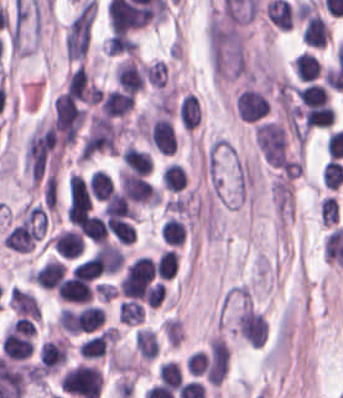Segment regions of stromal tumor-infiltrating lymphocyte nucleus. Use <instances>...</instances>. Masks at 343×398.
Returning <instances> with one entry per match:
<instances>
[{
    "label": "stromal tumor-infiltrating lymphocyte nucleus",
    "instance_id": "1",
    "mask_svg": "<svg viewBox=\"0 0 343 398\" xmlns=\"http://www.w3.org/2000/svg\"><path fill=\"white\" fill-rule=\"evenodd\" d=\"M56 291L64 303H90L95 291L93 276L82 264H75L56 286Z\"/></svg>",
    "mask_w": 343,
    "mask_h": 398
},
{
    "label": "stromal tumor-infiltrating lymphocyte nucleus",
    "instance_id": "2",
    "mask_svg": "<svg viewBox=\"0 0 343 398\" xmlns=\"http://www.w3.org/2000/svg\"><path fill=\"white\" fill-rule=\"evenodd\" d=\"M235 107L242 122H257L271 109L266 92L252 86H245L235 93Z\"/></svg>",
    "mask_w": 343,
    "mask_h": 398
},
{
    "label": "stromal tumor-infiltrating lymphocyte nucleus",
    "instance_id": "3",
    "mask_svg": "<svg viewBox=\"0 0 343 398\" xmlns=\"http://www.w3.org/2000/svg\"><path fill=\"white\" fill-rule=\"evenodd\" d=\"M148 141L161 154H173L176 146L173 122L168 114L155 113L146 125Z\"/></svg>",
    "mask_w": 343,
    "mask_h": 398
},
{
    "label": "stromal tumor-infiltrating lymphocyte nucleus",
    "instance_id": "4",
    "mask_svg": "<svg viewBox=\"0 0 343 398\" xmlns=\"http://www.w3.org/2000/svg\"><path fill=\"white\" fill-rule=\"evenodd\" d=\"M155 263L145 256L136 257L125 269L120 290H144L154 279Z\"/></svg>",
    "mask_w": 343,
    "mask_h": 398
},
{
    "label": "stromal tumor-infiltrating lymphocyte nucleus",
    "instance_id": "5",
    "mask_svg": "<svg viewBox=\"0 0 343 398\" xmlns=\"http://www.w3.org/2000/svg\"><path fill=\"white\" fill-rule=\"evenodd\" d=\"M65 274V264L59 258L49 257L33 271V283L43 289H56Z\"/></svg>",
    "mask_w": 343,
    "mask_h": 398
},
{
    "label": "stromal tumor-infiltrating lymphocyte nucleus",
    "instance_id": "6",
    "mask_svg": "<svg viewBox=\"0 0 343 398\" xmlns=\"http://www.w3.org/2000/svg\"><path fill=\"white\" fill-rule=\"evenodd\" d=\"M49 243L64 257L75 258L83 250V237L75 228H61L53 233Z\"/></svg>",
    "mask_w": 343,
    "mask_h": 398
},
{
    "label": "stromal tumor-infiltrating lymphocyte nucleus",
    "instance_id": "7",
    "mask_svg": "<svg viewBox=\"0 0 343 398\" xmlns=\"http://www.w3.org/2000/svg\"><path fill=\"white\" fill-rule=\"evenodd\" d=\"M122 157L127 169L146 175L153 169L152 154L148 149L127 143L122 149Z\"/></svg>",
    "mask_w": 343,
    "mask_h": 398
},
{
    "label": "stromal tumor-infiltrating lymphocyte nucleus",
    "instance_id": "8",
    "mask_svg": "<svg viewBox=\"0 0 343 398\" xmlns=\"http://www.w3.org/2000/svg\"><path fill=\"white\" fill-rule=\"evenodd\" d=\"M178 115L185 130L194 131L202 121L200 98L193 93H185L179 106Z\"/></svg>",
    "mask_w": 343,
    "mask_h": 398
},
{
    "label": "stromal tumor-infiltrating lymphocyte nucleus",
    "instance_id": "9",
    "mask_svg": "<svg viewBox=\"0 0 343 398\" xmlns=\"http://www.w3.org/2000/svg\"><path fill=\"white\" fill-rule=\"evenodd\" d=\"M299 110L308 128H325L333 125L335 113L328 103L299 106Z\"/></svg>",
    "mask_w": 343,
    "mask_h": 398
},
{
    "label": "stromal tumor-infiltrating lymphocyte nucleus",
    "instance_id": "10",
    "mask_svg": "<svg viewBox=\"0 0 343 398\" xmlns=\"http://www.w3.org/2000/svg\"><path fill=\"white\" fill-rule=\"evenodd\" d=\"M294 74L299 81H313L320 76L323 69L318 57L312 51H303L295 58Z\"/></svg>",
    "mask_w": 343,
    "mask_h": 398
},
{
    "label": "stromal tumor-infiltrating lymphocyte nucleus",
    "instance_id": "11",
    "mask_svg": "<svg viewBox=\"0 0 343 398\" xmlns=\"http://www.w3.org/2000/svg\"><path fill=\"white\" fill-rule=\"evenodd\" d=\"M1 349L13 360H25L34 351V343L28 335L3 336Z\"/></svg>",
    "mask_w": 343,
    "mask_h": 398
},
{
    "label": "stromal tumor-infiltrating lymphocyte nucleus",
    "instance_id": "12",
    "mask_svg": "<svg viewBox=\"0 0 343 398\" xmlns=\"http://www.w3.org/2000/svg\"><path fill=\"white\" fill-rule=\"evenodd\" d=\"M77 327L79 331H93L100 329L104 320V311L93 303H86L76 309Z\"/></svg>",
    "mask_w": 343,
    "mask_h": 398
},
{
    "label": "stromal tumor-infiltrating lymphocyte nucleus",
    "instance_id": "13",
    "mask_svg": "<svg viewBox=\"0 0 343 398\" xmlns=\"http://www.w3.org/2000/svg\"><path fill=\"white\" fill-rule=\"evenodd\" d=\"M136 351L139 358L151 360L158 355V336L147 326H139L136 331Z\"/></svg>",
    "mask_w": 343,
    "mask_h": 398
},
{
    "label": "stromal tumor-infiltrating lymphocyte nucleus",
    "instance_id": "14",
    "mask_svg": "<svg viewBox=\"0 0 343 398\" xmlns=\"http://www.w3.org/2000/svg\"><path fill=\"white\" fill-rule=\"evenodd\" d=\"M294 92L301 104L322 105L329 102V96L324 85L309 82L294 88Z\"/></svg>",
    "mask_w": 343,
    "mask_h": 398
},
{
    "label": "stromal tumor-infiltrating lymphocyte nucleus",
    "instance_id": "15",
    "mask_svg": "<svg viewBox=\"0 0 343 398\" xmlns=\"http://www.w3.org/2000/svg\"><path fill=\"white\" fill-rule=\"evenodd\" d=\"M161 237L168 246H181L186 237V227L179 217L167 216L162 227Z\"/></svg>",
    "mask_w": 343,
    "mask_h": 398
},
{
    "label": "stromal tumor-infiltrating lymphocyte nucleus",
    "instance_id": "16",
    "mask_svg": "<svg viewBox=\"0 0 343 398\" xmlns=\"http://www.w3.org/2000/svg\"><path fill=\"white\" fill-rule=\"evenodd\" d=\"M70 273L94 279L103 274L102 250H95L77 262Z\"/></svg>",
    "mask_w": 343,
    "mask_h": 398
},
{
    "label": "stromal tumor-infiltrating lymphocyte nucleus",
    "instance_id": "17",
    "mask_svg": "<svg viewBox=\"0 0 343 398\" xmlns=\"http://www.w3.org/2000/svg\"><path fill=\"white\" fill-rule=\"evenodd\" d=\"M100 251L104 272L114 274L121 269L124 263V254L121 246L113 242H100Z\"/></svg>",
    "mask_w": 343,
    "mask_h": 398
},
{
    "label": "stromal tumor-infiltrating lymphocyte nucleus",
    "instance_id": "18",
    "mask_svg": "<svg viewBox=\"0 0 343 398\" xmlns=\"http://www.w3.org/2000/svg\"><path fill=\"white\" fill-rule=\"evenodd\" d=\"M162 182L167 191H180L186 187L188 179L180 164L168 163L162 170Z\"/></svg>",
    "mask_w": 343,
    "mask_h": 398
},
{
    "label": "stromal tumor-infiltrating lymphocyte nucleus",
    "instance_id": "19",
    "mask_svg": "<svg viewBox=\"0 0 343 398\" xmlns=\"http://www.w3.org/2000/svg\"><path fill=\"white\" fill-rule=\"evenodd\" d=\"M144 314L142 303L136 299L122 298L117 308L118 321L127 325H134Z\"/></svg>",
    "mask_w": 343,
    "mask_h": 398
},
{
    "label": "stromal tumor-infiltrating lymphocyte nucleus",
    "instance_id": "20",
    "mask_svg": "<svg viewBox=\"0 0 343 398\" xmlns=\"http://www.w3.org/2000/svg\"><path fill=\"white\" fill-rule=\"evenodd\" d=\"M179 266L178 251L166 248L157 259V274L159 278L171 279L177 272Z\"/></svg>",
    "mask_w": 343,
    "mask_h": 398
},
{
    "label": "stromal tumor-infiltrating lymphocyte nucleus",
    "instance_id": "21",
    "mask_svg": "<svg viewBox=\"0 0 343 398\" xmlns=\"http://www.w3.org/2000/svg\"><path fill=\"white\" fill-rule=\"evenodd\" d=\"M321 178L324 187L338 189L343 182V164L336 158H329L321 170Z\"/></svg>",
    "mask_w": 343,
    "mask_h": 398
},
{
    "label": "stromal tumor-infiltrating lymphocyte nucleus",
    "instance_id": "22",
    "mask_svg": "<svg viewBox=\"0 0 343 398\" xmlns=\"http://www.w3.org/2000/svg\"><path fill=\"white\" fill-rule=\"evenodd\" d=\"M161 326L163 328L166 339L171 344V346L174 349L178 347L185 336V326L183 319L179 318L176 315L169 318H164Z\"/></svg>",
    "mask_w": 343,
    "mask_h": 398
},
{
    "label": "stromal tumor-infiltrating lymphocyte nucleus",
    "instance_id": "23",
    "mask_svg": "<svg viewBox=\"0 0 343 398\" xmlns=\"http://www.w3.org/2000/svg\"><path fill=\"white\" fill-rule=\"evenodd\" d=\"M319 219L322 226H331L339 218V206L333 195L321 197L318 203Z\"/></svg>",
    "mask_w": 343,
    "mask_h": 398
},
{
    "label": "stromal tumor-infiltrating lymphocyte nucleus",
    "instance_id": "24",
    "mask_svg": "<svg viewBox=\"0 0 343 398\" xmlns=\"http://www.w3.org/2000/svg\"><path fill=\"white\" fill-rule=\"evenodd\" d=\"M82 232L92 243L98 244L105 241V231L102 219L96 214L88 215L82 226Z\"/></svg>",
    "mask_w": 343,
    "mask_h": 398
},
{
    "label": "stromal tumor-infiltrating lymphocyte nucleus",
    "instance_id": "25",
    "mask_svg": "<svg viewBox=\"0 0 343 398\" xmlns=\"http://www.w3.org/2000/svg\"><path fill=\"white\" fill-rule=\"evenodd\" d=\"M163 383L170 387H180L183 383L180 364L174 360L162 362L158 369Z\"/></svg>",
    "mask_w": 343,
    "mask_h": 398
},
{
    "label": "stromal tumor-infiltrating lymphocyte nucleus",
    "instance_id": "26",
    "mask_svg": "<svg viewBox=\"0 0 343 398\" xmlns=\"http://www.w3.org/2000/svg\"><path fill=\"white\" fill-rule=\"evenodd\" d=\"M36 324L34 320L24 317H17L7 324L3 330L6 336L35 335Z\"/></svg>",
    "mask_w": 343,
    "mask_h": 398
},
{
    "label": "stromal tumor-infiltrating lymphocyte nucleus",
    "instance_id": "27",
    "mask_svg": "<svg viewBox=\"0 0 343 398\" xmlns=\"http://www.w3.org/2000/svg\"><path fill=\"white\" fill-rule=\"evenodd\" d=\"M185 367L190 376H204L207 369L206 351L196 350L185 359Z\"/></svg>",
    "mask_w": 343,
    "mask_h": 398
},
{
    "label": "stromal tumor-infiltrating lymphocyte nucleus",
    "instance_id": "28",
    "mask_svg": "<svg viewBox=\"0 0 343 398\" xmlns=\"http://www.w3.org/2000/svg\"><path fill=\"white\" fill-rule=\"evenodd\" d=\"M111 181L102 170H95L90 175L91 197L102 201Z\"/></svg>",
    "mask_w": 343,
    "mask_h": 398
}]
</instances>
